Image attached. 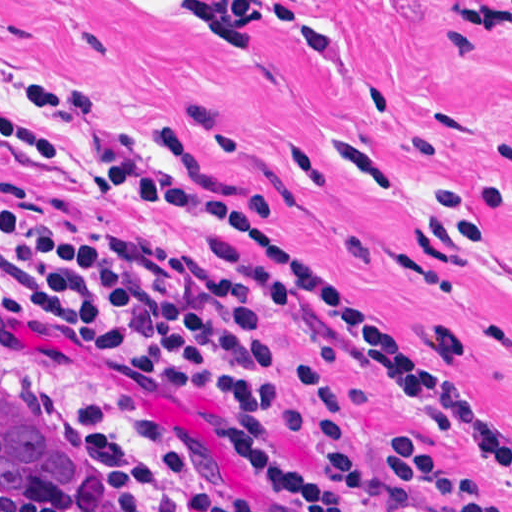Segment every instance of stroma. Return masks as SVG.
I'll list each match as a JSON object with an SVG mask.
<instances>
[{
	"label": "stroma",
	"mask_w": 512,
	"mask_h": 512,
	"mask_svg": "<svg viewBox=\"0 0 512 512\" xmlns=\"http://www.w3.org/2000/svg\"><path fill=\"white\" fill-rule=\"evenodd\" d=\"M0 353L63 410L81 442L130 468L126 499L38 512H166L185 473L229 481L260 512L280 492L215 444L209 397L116 373L81 328L57 351L20 339L14 212L148 236L238 292L298 411L295 360L334 395L365 455L413 435L512 512V23L463 28L452 0H195L173 23H133L106 0H0ZM78 150L167 156L257 234L283 244L404 326L487 456L425 417L408 387L348 340L272 304L225 256L245 241L191 239ZM277 442L346 512L323 438Z\"/></svg>",
	"instance_id": "1"
}]
</instances>
